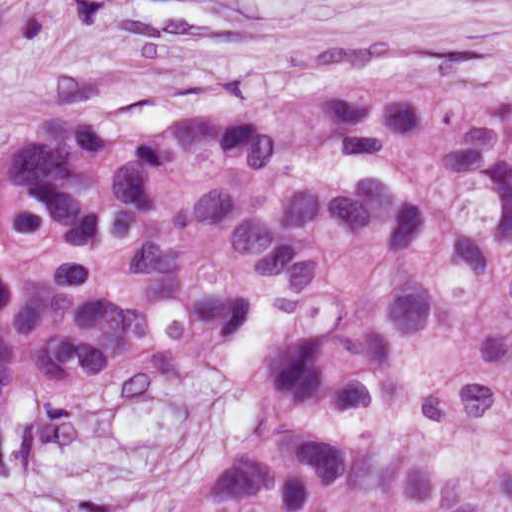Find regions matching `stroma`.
<instances>
[{"mask_svg": "<svg viewBox=\"0 0 512 512\" xmlns=\"http://www.w3.org/2000/svg\"><path fill=\"white\" fill-rule=\"evenodd\" d=\"M512 70V0H73L0 68V158L73 116L149 124L216 93H293L409 60ZM246 403L218 366H164L28 425L0 512H173L233 460Z\"/></svg>", "mask_w": 512, "mask_h": 512, "instance_id": "35a3bbf8", "label": "stroma"}]
</instances>
